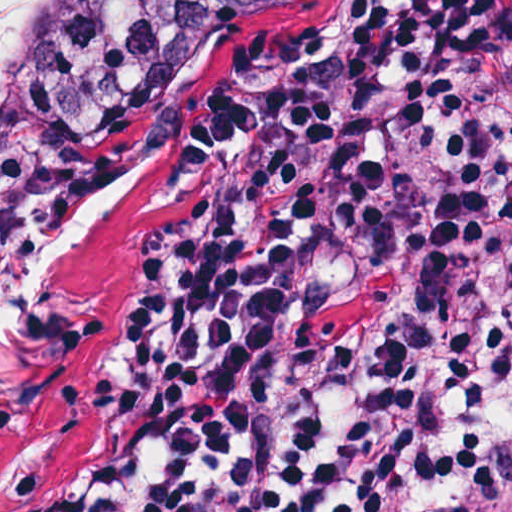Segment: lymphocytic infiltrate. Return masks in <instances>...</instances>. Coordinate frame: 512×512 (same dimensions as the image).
I'll use <instances>...</instances> for the list:
<instances>
[{"instance_id":"f902f5d3","label":"lymphocytic infiltrate","mask_w":512,"mask_h":512,"mask_svg":"<svg viewBox=\"0 0 512 512\" xmlns=\"http://www.w3.org/2000/svg\"><path fill=\"white\" fill-rule=\"evenodd\" d=\"M285 190L166 258L118 416L0 512H512V0H412L253 116Z\"/></svg>"}]
</instances>
